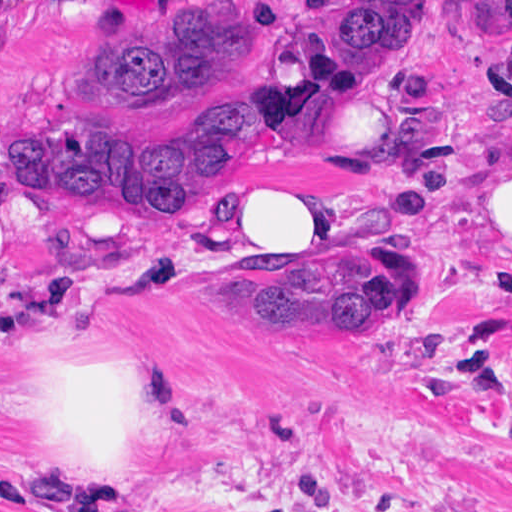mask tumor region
I'll return each mask as SVG.
<instances>
[{
    "mask_svg": "<svg viewBox=\"0 0 512 512\" xmlns=\"http://www.w3.org/2000/svg\"><path fill=\"white\" fill-rule=\"evenodd\" d=\"M427 15L428 0H313L271 30L262 0H204L123 18L80 65L70 91L82 112L55 132L2 144L0 175L15 192L103 212H196L240 184L266 149L302 157L325 113L399 72ZM264 52L265 96L238 77ZM230 79L220 135L204 148L146 144L102 121ZM174 274L267 335L374 331L423 308L440 283L430 255L396 241H338L337 258L307 268L234 248ZM0 512L27 510L0 492Z\"/></svg>",
    "mask_w": 512,
    "mask_h": 512,
    "instance_id": "tumor-region-1",
    "label": "tumor region"
}]
</instances>
